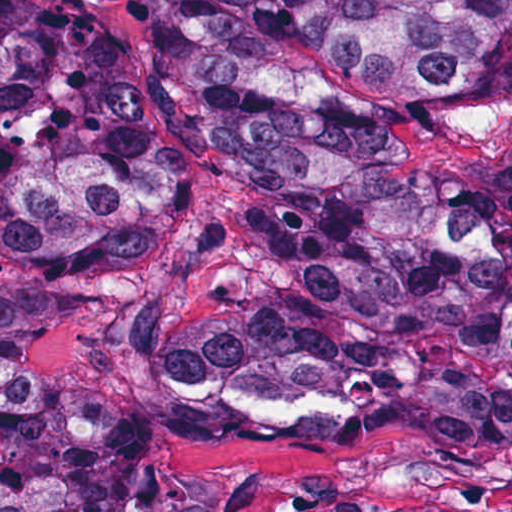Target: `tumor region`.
<instances>
[{
  "label": "tumor region",
  "instance_id": "obj_1",
  "mask_svg": "<svg viewBox=\"0 0 512 512\" xmlns=\"http://www.w3.org/2000/svg\"><path fill=\"white\" fill-rule=\"evenodd\" d=\"M469 0H158L83 20L0 0V261L39 281L144 273L200 133L244 186L209 269L141 297L130 361L174 393L267 361L359 350H500L512 258L446 226L432 169L394 158L377 111L290 72L334 59L430 101H466L445 45ZM73 310L0 284V512H220V485L153 478L148 426L50 394L24 350ZM299 512L372 507L348 494Z\"/></svg>",
  "mask_w": 512,
  "mask_h": 512
}]
</instances>
